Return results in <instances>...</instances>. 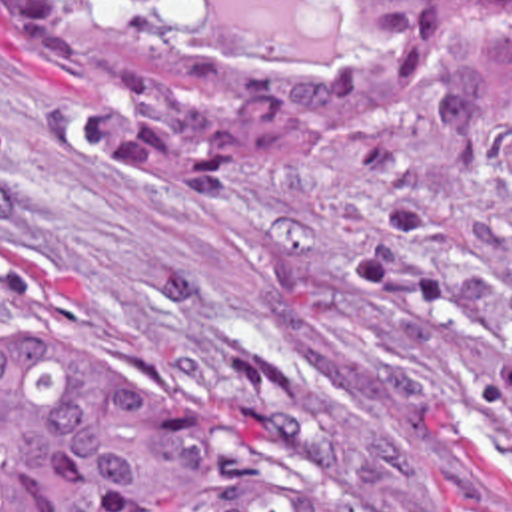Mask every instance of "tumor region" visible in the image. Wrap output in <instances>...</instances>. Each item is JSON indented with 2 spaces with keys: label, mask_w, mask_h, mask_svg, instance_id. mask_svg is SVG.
I'll return each instance as SVG.
<instances>
[{
  "label": "tumor region",
  "mask_w": 512,
  "mask_h": 512,
  "mask_svg": "<svg viewBox=\"0 0 512 512\" xmlns=\"http://www.w3.org/2000/svg\"><path fill=\"white\" fill-rule=\"evenodd\" d=\"M155 20L185 0H123ZM512 16V0H483ZM343 56L193 50L89 0H0L65 64L103 173L149 193H245L293 129L389 110L433 66V0H353ZM0 512H337L307 499L113 345L0 335Z\"/></svg>",
  "instance_id": "e687c5a6"
}]
</instances>
